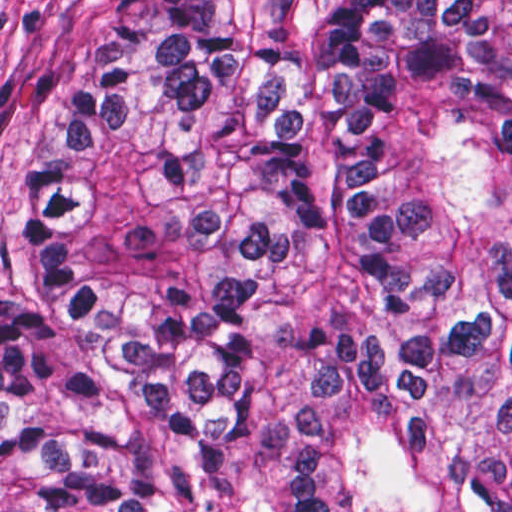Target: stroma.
<instances>
[{
	"label": "stroma",
	"instance_id": "35a3bbf8",
	"mask_svg": "<svg viewBox=\"0 0 512 512\" xmlns=\"http://www.w3.org/2000/svg\"><path fill=\"white\" fill-rule=\"evenodd\" d=\"M145 0H0V290L29 226V189L68 136L99 52Z\"/></svg>",
	"mask_w": 512,
	"mask_h": 512
}]
</instances>
